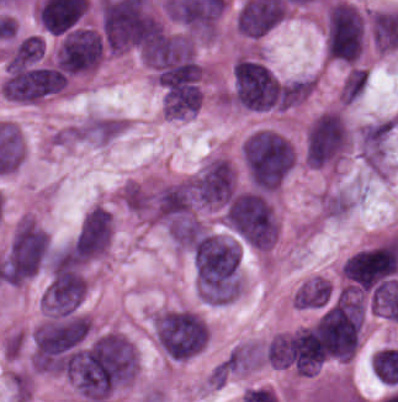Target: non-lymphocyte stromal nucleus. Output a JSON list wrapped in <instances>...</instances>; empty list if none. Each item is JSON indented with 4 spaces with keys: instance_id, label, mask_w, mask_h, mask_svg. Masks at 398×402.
Wrapping results in <instances>:
<instances>
[{
    "instance_id": "dd21d789",
    "label": "non-lymphocyte stromal nucleus",
    "mask_w": 398,
    "mask_h": 402,
    "mask_svg": "<svg viewBox=\"0 0 398 402\" xmlns=\"http://www.w3.org/2000/svg\"><path fill=\"white\" fill-rule=\"evenodd\" d=\"M84 134L82 126L78 124L62 126L51 135L50 143L58 147L72 146L83 139Z\"/></svg>"
}]
</instances>
